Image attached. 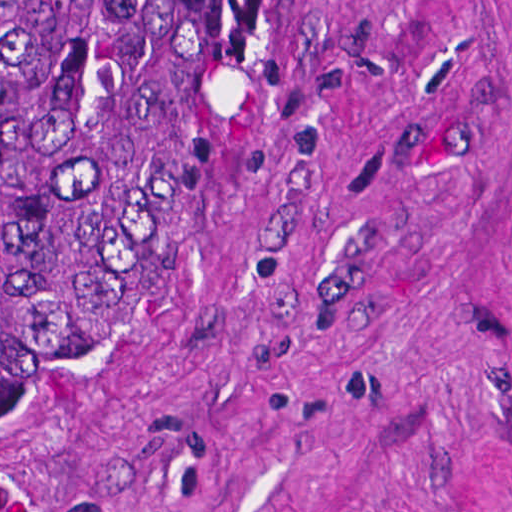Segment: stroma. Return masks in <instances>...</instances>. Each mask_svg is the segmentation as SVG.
<instances>
[{
  "label": "stroma",
  "instance_id": "1",
  "mask_svg": "<svg viewBox=\"0 0 512 512\" xmlns=\"http://www.w3.org/2000/svg\"><path fill=\"white\" fill-rule=\"evenodd\" d=\"M0 512H512V0H213Z\"/></svg>",
  "mask_w": 512,
  "mask_h": 512
}]
</instances>
